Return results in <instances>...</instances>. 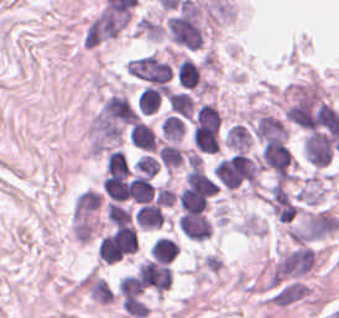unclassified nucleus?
<instances>
[{
  "label": "unclassified nucleus",
  "instance_id": "unclassified-nucleus-9",
  "mask_svg": "<svg viewBox=\"0 0 339 318\" xmlns=\"http://www.w3.org/2000/svg\"><path fill=\"white\" fill-rule=\"evenodd\" d=\"M160 103V91L151 86H144L138 93L137 105L140 113L150 114L155 111Z\"/></svg>",
  "mask_w": 339,
  "mask_h": 318
},
{
  "label": "unclassified nucleus",
  "instance_id": "unclassified-nucleus-10",
  "mask_svg": "<svg viewBox=\"0 0 339 318\" xmlns=\"http://www.w3.org/2000/svg\"><path fill=\"white\" fill-rule=\"evenodd\" d=\"M160 163L154 155L143 154L140 155L135 163V173L142 174L149 177L154 175L159 170Z\"/></svg>",
  "mask_w": 339,
  "mask_h": 318
},
{
  "label": "unclassified nucleus",
  "instance_id": "unclassified-nucleus-6",
  "mask_svg": "<svg viewBox=\"0 0 339 318\" xmlns=\"http://www.w3.org/2000/svg\"><path fill=\"white\" fill-rule=\"evenodd\" d=\"M200 79V67L193 63L190 59H183L178 64V83L179 85L193 89Z\"/></svg>",
  "mask_w": 339,
  "mask_h": 318
},
{
  "label": "unclassified nucleus",
  "instance_id": "unclassified-nucleus-8",
  "mask_svg": "<svg viewBox=\"0 0 339 318\" xmlns=\"http://www.w3.org/2000/svg\"><path fill=\"white\" fill-rule=\"evenodd\" d=\"M160 131L166 140H180L184 134L180 116L168 113L160 122Z\"/></svg>",
  "mask_w": 339,
  "mask_h": 318
},
{
  "label": "unclassified nucleus",
  "instance_id": "unclassified-nucleus-3",
  "mask_svg": "<svg viewBox=\"0 0 339 318\" xmlns=\"http://www.w3.org/2000/svg\"><path fill=\"white\" fill-rule=\"evenodd\" d=\"M138 225L144 228H159L165 223L161 206L154 204H140L136 213Z\"/></svg>",
  "mask_w": 339,
  "mask_h": 318
},
{
  "label": "unclassified nucleus",
  "instance_id": "unclassified-nucleus-1",
  "mask_svg": "<svg viewBox=\"0 0 339 318\" xmlns=\"http://www.w3.org/2000/svg\"><path fill=\"white\" fill-rule=\"evenodd\" d=\"M178 228L191 241L201 242L205 241L212 231L210 221L203 213H190L181 216Z\"/></svg>",
  "mask_w": 339,
  "mask_h": 318
},
{
  "label": "unclassified nucleus",
  "instance_id": "unclassified-nucleus-5",
  "mask_svg": "<svg viewBox=\"0 0 339 318\" xmlns=\"http://www.w3.org/2000/svg\"><path fill=\"white\" fill-rule=\"evenodd\" d=\"M166 102L178 115L190 117L194 112V104L190 93L184 91H170Z\"/></svg>",
  "mask_w": 339,
  "mask_h": 318
},
{
  "label": "unclassified nucleus",
  "instance_id": "unclassified-nucleus-2",
  "mask_svg": "<svg viewBox=\"0 0 339 318\" xmlns=\"http://www.w3.org/2000/svg\"><path fill=\"white\" fill-rule=\"evenodd\" d=\"M128 138L137 148L147 150H155L158 143L152 128L139 120L130 127Z\"/></svg>",
  "mask_w": 339,
  "mask_h": 318
},
{
  "label": "unclassified nucleus",
  "instance_id": "unclassified-nucleus-7",
  "mask_svg": "<svg viewBox=\"0 0 339 318\" xmlns=\"http://www.w3.org/2000/svg\"><path fill=\"white\" fill-rule=\"evenodd\" d=\"M186 152L171 143H164L157 149V156L166 168L182 164Z\"/></svg>",
  "mask_w": 339,
  "mask_h": 318
},
{
  "label": "unclassified nucleus",
  "instance_id": "unclassified-nucleus-4",
  "mask_svg": "<svg viewBox=\"0 0 339 318\" xmlns=\"http://www.w3.org/2000/svg\"><path fill=\"white\" fill-rule=\"evenodd\" d=\"M179 249L171 237L158 236L150 247L153 261L171 263L178 255Z\"/></svg>",
  "mask_w": 339,
  "mask_h": 318
}]
</instances>
